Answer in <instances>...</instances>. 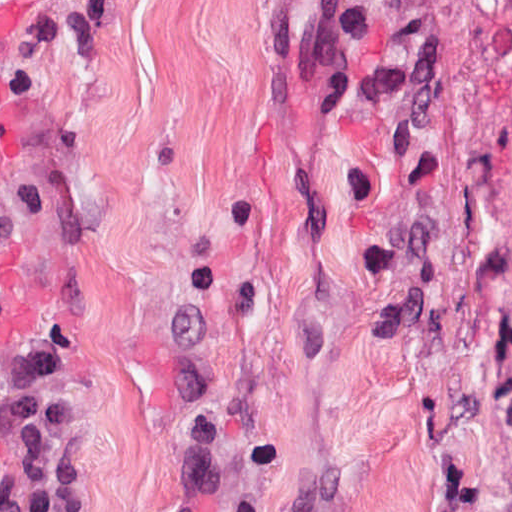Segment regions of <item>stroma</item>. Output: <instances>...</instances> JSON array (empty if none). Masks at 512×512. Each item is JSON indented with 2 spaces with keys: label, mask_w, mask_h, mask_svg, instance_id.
Wrapping results in <instances>:
<instances>
[{
  "label": "stroma",
  "mask_w": 512,
  "mask_h": 512,
  "mask_svg": "<svg viewBox=\"0 0 512 512\" xmlns=\"http://www.w3.org/2000/svg\"><path fill=\"white\" fill-rule=\"evenodd\" d=\"M16 68L0 356L90 512H512V0H0Z\"/></svg>",
  "instance_id": "obj_1"
}]
</instances>
